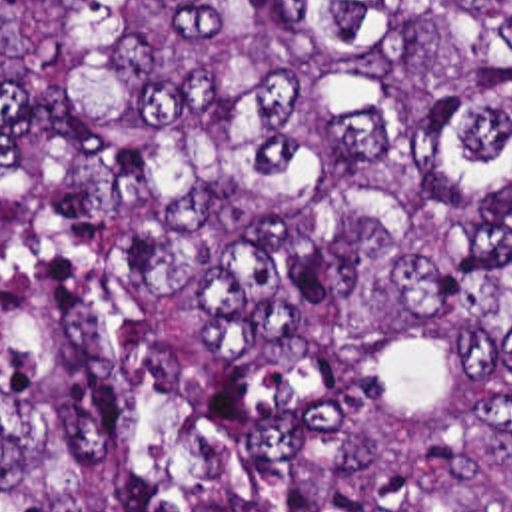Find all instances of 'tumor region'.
Wrapping results in <instances>:
<instances>
[{
    "mask_svg": "<svg viewBox=\"0 0 512 512\" xmlns=\"http://www.w3.org/2000/svg\"><path fill=\"white\" fill-rule=\"evenodd\" d=\"M0 512H512V0H0Z\"/></svg>",
    "mask_w": 512,
    "mask_h": 512,
    "instance_id": "1",
    "label": "tumor region"
}]
</instances>
